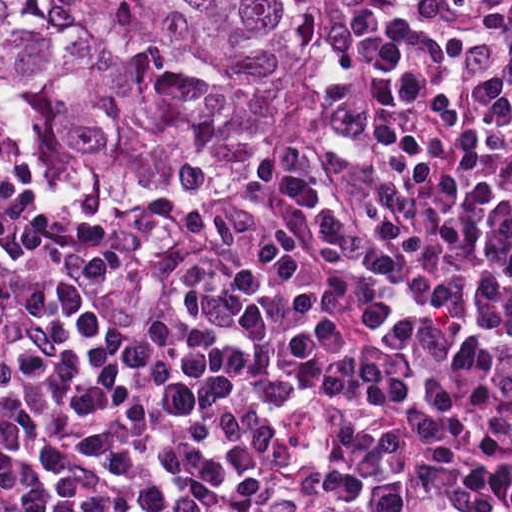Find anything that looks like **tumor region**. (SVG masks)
I'll return each mask as SVG.
<instances>
[{
  "instance_id": "obj_1",
  "label": "tumor region",
  "mask_w": 512,
  "mask_h": 512,
  "mask_svg": "<svg viewBox=\"0 0 512 512\" xmlns=\"http://www.w3.org/2000/svg\"><path fill=\"white\" fill-rule=\"evenodd\" d=\"M334 0H0V132L45 205H186L277 157Z\"/></svg>"
}]
</instances>
